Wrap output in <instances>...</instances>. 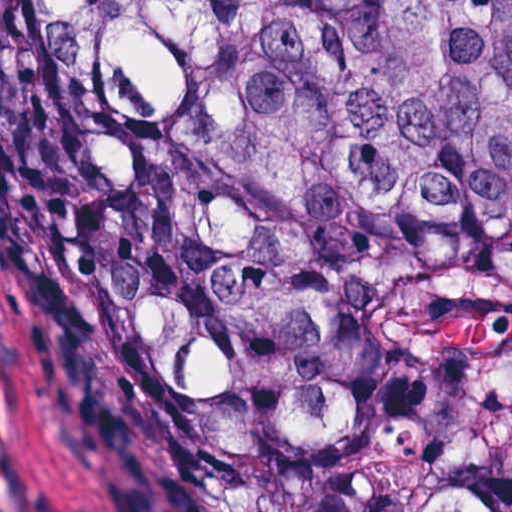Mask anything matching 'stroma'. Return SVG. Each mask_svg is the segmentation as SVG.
<instances>
[{
    "mask_svg": "<svg viewBox=\"0 0 512 512\" xmlns=\"http://www.w3.org/2000/svg\"><path fill=\"white\" fill-rule=\"evenodd\" d=\"M7 512H157L0 132Z\"/></svg>",
    "mask_w": 512,
    "mask_h": 512,
    "instance_id": "stroma-1",
    "label": "stroma"
}]
</instances>
